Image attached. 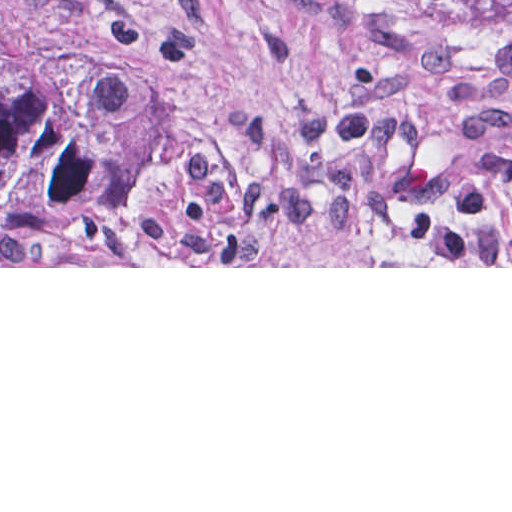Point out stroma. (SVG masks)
<instances>
[{"mask_svg":"<svg viewBox=\"0 0 512 512\" xmlns=\"http://www.w3.org/2000/svg\"><path fill=\"white\" fill-rule=\"evenodd\" d=\"M0 268H512V28L0 0Z\"/></svg>","mask_w":512,"mask_h":512,"instance_id":"obj_1","label":"stroma"}]
</instances>
